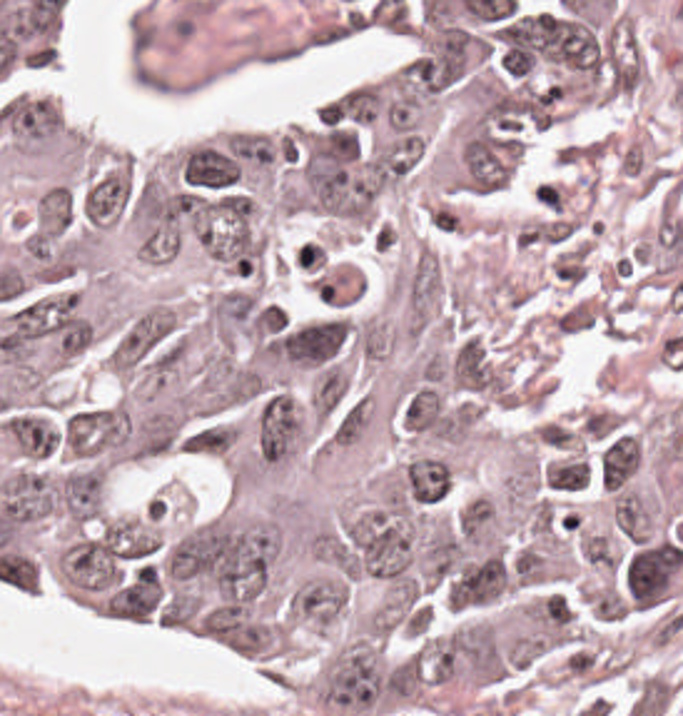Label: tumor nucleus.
<instances>
[{
    "mask_svg": "<svg viewBox=\"0 0 683 716\" xmlns=\"http://www.w3.org/2000/svg\"><path fill=\"white\" fill-rule=\"evenodd\" d=\"M683 560L679 546L657 540L623 561V586L633 607L646 608L664 593Z\"/></svg>",
    "mask_w": 683,
    "mask_h": 716,
    "instance_id": "tumor-nucleus-3",
    "label": "tumor nucleus"
},
{
    "mask_svg": "<svg viewBox=\"0 0 683 716\" xmlns=\"http://www.w3.org/2000/svg\"><path fill=\"white\" fill-rule=\"evenodd\" d=\"M136 428L135 414L112 401L76 406L61 426L66 452L94 467L130 452Z\"/></svg>",
    "mask_w": 683,
    "mask_h": 716,
    "instance_id": "tumor-nucleus-2",
    "label": "tumor nucleus"
},
{
    "mask_svg": "<svg viewBox=\"0 0 683 716\" xmlns=\"http://www.w3.org/2000/svg\"><path fill=\"white\" fill-rule=\"evenodd\" d=\"M316 692L333 709L361 716L382 712L399 698V668L372 641L336 653L316 678Z\"/></svg>",
    "mask_w": 683,
    "mask_h": 716,
    "instance_id": "tumor-nucleus-1",
    "label": "tumor nucleus"
}]
</instances>
